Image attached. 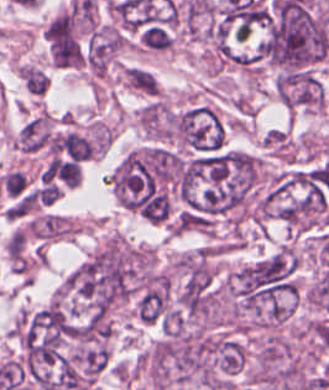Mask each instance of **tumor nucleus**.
I'll list each match as a JSON object with an SVG mask.
<instances>
[{"label":"tumor nucleus","mask_w":329,"mask_h":390,"mask_svg":"<svg viewBox=\"0 0 329 390\" xmlns=\"http://www.w3.org/2000/svg\"><path fill=\"white\" fill-rule=\"evenodd\" d=\"M274 84L279 101L288 108L308 111L324 104V85L313 72L282 70Z\"/></svg>","instance_id":"2f306a5c"},{"label":"tumor nucleus","mask_w":329,"mask_h":390,"mask_svg":"<svg viewBox=\"0 0 329 390\" xmlns=\"http://www.w3.org/2000/svg\"><path fill=\"white\" fill-rule=\"evenodd\" d=\"M170 305V288L166 284L145 287L135 302V314L144 324L164 320Z\"/></svg>","instance_id":"8643909e"},{"label":"tumor nucleus","mask_w":329,"mask_h":390,"mask_svg":"<svg viewBox=\"0 0 329 390\" xmlns=\"http://www.w3.org/2000/svg\"><path fill=\"white\" fill-rule=\"evenodd\" d=\"M75 230L66 216L53 212L35 215L28 224L29 233L47 242L73 236Z\"/></svg>","instance_id":"5ab6c2c4"},{"label":"tumor nucleus","mask_w":329,"mask_h":390,"mask_svg":"<svg viewBox=\"0 0 329 390\" xmlns=\"http://www.w3.org/2000/svg\"><path fill=\"white\" fill-rule=\"evenodd\" d=\"M123 77L129 88L144 94H156L158 84L151 73L145 69L136 66H129Z\"/></svg>","instance_id":"2cbd58db"}]
</instances>
